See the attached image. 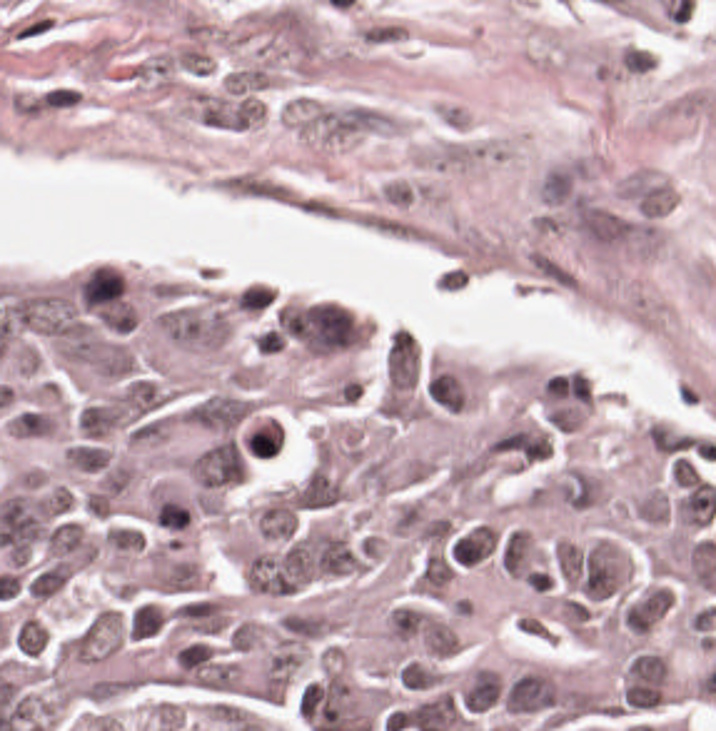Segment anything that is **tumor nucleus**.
I'll return each mask as SVG.
<instances>
[{
  "mask_svg": "<svg viewBox=\"0 0 716 731\" xmlns=\"http://www.w3.org/2000/svg\"><path fill=\"white\" fill-rule=\"evenodd\" d=\"M417 353L407 329H394L386 339L384 382L397 396L414 385Z\"/></svg>",
  "mask_w": 716,
  "mask_h": 731,
  "instance_id": "5",
  "label": "tumor nucleus"
},
{
  "mask_svg": "<svg viewBox=\"0 0 716 731\" xmlns=\"http://www.w3.org/2000/svg\"><path fill=\"white\" fill-rule=\"evenodd\" d=\"M291 492L330 512L340 507L347 497L346 477L335 459L319 454Z\"/></svg>",
  "mask_w": 716,
  "mask_h": 731,
  "instance_id": "4",
  "label": "tumor nucleus"
},
{
  "mask_svg": "<svg viewBox=\"0 0 716 731\" xmlns=\"http://www.w3.org/2000/svg\"><path fill=\"white\" fill-rule=\"evenodd\" d=\"M242 475V462L236 447L217 437L206 444L190 461L186 480L196 487L218 489Z\"/></svg>",
  "mask_w": 716,
  "mask_h": 731,
  "instance_id": "3",
  "label": "tumor nucleus"
},
{
  "mask_svg": "<svg viewBox=\"0 0 716 731\" xmlns=\"http://www.w3.org/2000/svg\"><path fill=\"white\" fill-rule=\"evenodd\" d=\"M666 676L662 653L631 651L618 691L621 709H652L662 697Z\"/></svg>",
  "mask_w": 716,
  "mask_h": 731,
  "instance_id": "1",
  "label": "tumor nucleus"
},
{
  "mask_svg": "<svg viewBox=\"0 0 716 731\" xmlns=\"http://www.w3.org/2000/svg\"><path fill=\"white\" fill-rule=\"evenodd\" d=\"M672 607V589L659 579H646L620 600L616 623L621 632L643 636Z\"/></svg>",
  "mask_w": 716,
  "mask_h": 731,
  "instance_id": "2",
  "label": "tumor nucleus"
}]
</instances>
